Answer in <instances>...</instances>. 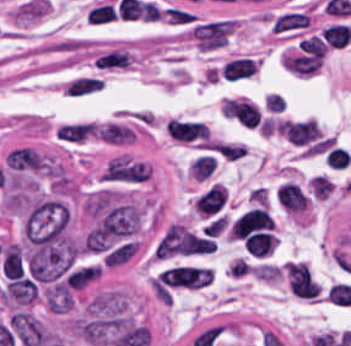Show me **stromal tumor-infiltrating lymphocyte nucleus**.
<instances>
[{"mask_svg":"<svg viewBox=\"0 0 351 346\" xmlns=\"http://www.w3.org/2000/svg\"><path fill=\"white\" fill-rule=\"evenodd\" d=\"M272 219L265 208L254 207L234 219L230 236L244 239L271 230Z\"/></svg>","mask_w":351,"mask_h":346,"instance_id":"stromal-tumor-infiltrating-lymphocyte-nucleus-1","label":"stromal tumor-infiltrating lymphocyte nucleus"},{"mask_svg":"<svg viewBox=\"0 0 351 346\" xmlns=\"http://www.w3.org/2000/svg\"><path fill=\"white\" fill-rule=\"evenodd\" d=\"M277 205L285 212L292 214L304 213L309 196L299 185L290 181H282L275 195Z\"/></svg>","mask_w":351,"mask_h":346,"instance_id":"stromal-tumor-infiltrating-lymphocyte-nucleus-2","label":"stromal tumor-infiltrating lymphocyte nucleus"},{"mask_svg":"<svg viewBox=\"0 0 351 346\" xmlns=\"http://www.w3.org/2000/svg\"><path fill=\"white\" fill-rule=\"evenodd\" d=\"M164 128L173 138L187 142L205 139L206 125L200 121L169 118Z\"/></svg>","mask_w":351,"mask_h":346,"instance_id":"stromal-tumor-infiltrating-lymphocyte-nucleus-3","label":"stromal tumor-infiltrating lymphocyte nucleus"},{"mask_svg":"<svg viewBox=\"0 0 351 346\" xmlns=\"http://www.w3.org/2000/svg\"><path fill=\"white\" fill-rule=\"evenodd\" d=\"M308 14L303 10L289 9L275 15L271 27L279 34H292L301 31L308 24Z\"/></svg>","mask_w":351,"mask_h":346,"instance_id":"stromal-tumor-infiltrating-lymphocyte-nucleus-4","label":"stromal tumor-infiltrating lymphocyte nucleus"},{"mask_svg":"<svg viewBox=\"0 0 351 346\" xmlns=\"http://www.w3.org/2000/svg\"><path fill=\"white\" fill-rule=\"evenodd\" d=\"M256 64L249 56H236L221 66V77L226 81H240L253 76Z\"/></svg>","mask_w":351,"mask_h":346,"instance_id":"stromal-tumor-infiltrating-lymphocyte-nucleus-5","label":"stromal tumor-infiltrating lymphocyte nucleus"},{"mask_svg":"<svg viewBox=\"0 0 351 346\" xmlns=\"http://www.w3.org/2000/svg\"><path fill=\"white\" fill-rule=\"evenodd\" d=\"M248 255L265 257L275 244L273 235L264 230H257L242 240Z\"/></svg>","mask_w":351,"mask_h":346,"instance_id":"stromal-tumor-infiltrating-lymphocyte-nucleus-6","label":"stromal tumor-infiltrating lymphocyte nucleus"},{"mask_svg":"<svg viewBox=\"0 0 351 346\" xmlns=\"http://www.w3.org/2000/svg\"><path fill=\"white\" fill-rule=\"evenodd\" d=\"M215 167V157L212 155H199L190 164L189 173L193 180L202 181L213 173Z\"/></svg>","mask_w":351,"mask_h":346,"instance_id":"stromal-tumor-infiltrating-lymphocyte-nucleus-7","label":"stromal tumor-infiltrating lymphocyte nucleus"}]
</instances>
